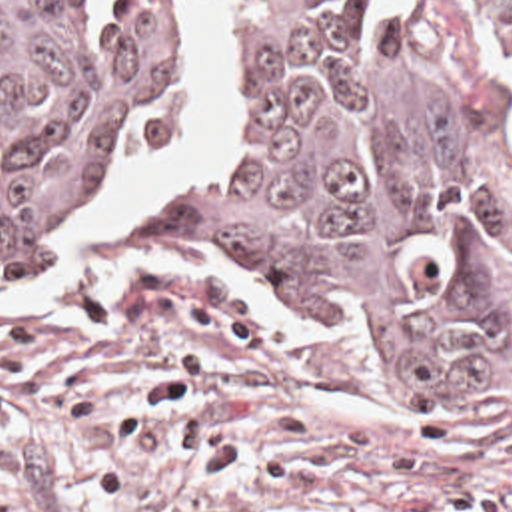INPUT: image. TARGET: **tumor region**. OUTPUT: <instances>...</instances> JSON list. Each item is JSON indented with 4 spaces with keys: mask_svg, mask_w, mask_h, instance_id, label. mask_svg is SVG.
I'll return each instance as SVG.
<instances>
[{
    "mask_svg": "<svg viewBox=\"0 0 512 512\" xmlns=\"http://www.w3.org/2000/svg\"><path fill=\"white\" fill-rule=\"evenodd\" d=\"M177 1L0 0V287L51 263L167 119ZM463 37L512 69V0H463ZM159 231L339 317L409 399L485 387V233L377 59L371 0H233L219 149Z\"/></svg>",
    "mask_w": 512,
    "mask_h": 512,
    "instance_id": "1",
    "label": "tumor region"
}]
</instances>
